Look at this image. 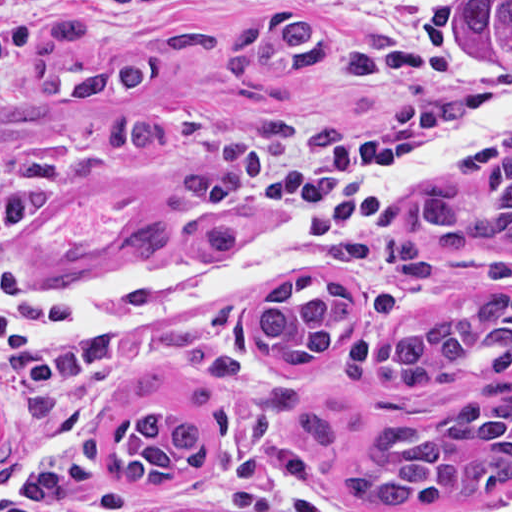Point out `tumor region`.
I'll use <instances>...</instances> for the list:
<instances>
[{
  "mask_svg": "<svg viewBox=\"0 0 512 512\" xmlns=\"http://www.w3.org/2000/svg\"><path fill=\"white\" fill-rule=\"evenodd\" d=\"M173 0H67L30 48V89L0 97V143L40 133L64 142L95 137L160 157L169 176L193 192L149 225L126 235L121 247L146 258L183 249L209 255L240 233L231 187L214 163L157 114L106 111L99 104L135 94L168 77L175 62L219 64L234 81L259 83L301 70L339 73L368 82L401 81L417 73V57L397 43L333 36L312 19L281 14L233 29L200 18L125 44L85 40L92 25L150 15ZM461 23L485 44L512 55V0H465ZM457 175L473 186L437 183L407 195L392 211L382 257L400 273L432 276L431 264L448 251L478 241L512 251V133L461 153ZM362 323V308L333 279L292 273L270 289L255 322L257 345L279 363L346 350ZM476 366L482 380L512 378V290L468 288L432 316L376 347L374 383L449 380ZM305 438L341 463L348 499L365 506L459 509L474 496L512 486V387L489 385L447 414L420 425H379L368 449L342 445L316 412L297 408ZM117 452L110 478L154 486L201 470L208 461L204 428L160 409H141L113 429Z\"/></svg>",
  "mask_w": 512,
  "mask_h": 512,
  "instance_id": "obj_1",
  "label": "tumor region"
}]
</instances>
